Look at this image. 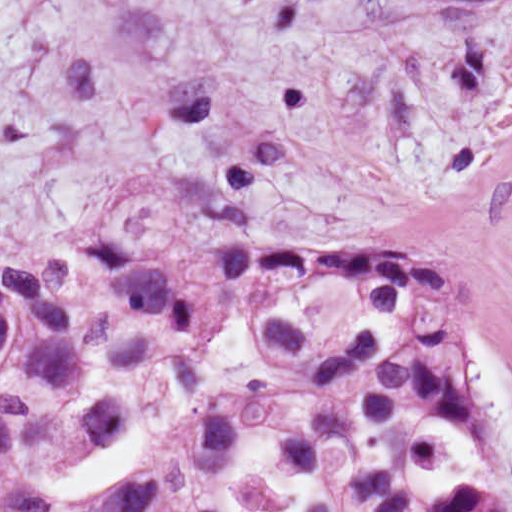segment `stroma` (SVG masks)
Instances as JSON below:
<instances>
[{
    "instance_id": "obj_1",
    "label": "stroma",
    "mask_w": 512,
    "mask_h": 512,
    "mask_svg": "<svg viewBox=\"0 0 512 512\" xmlns=\"http://www.w3.org/2000/svg\"><path fill=\"white\" fill-rule=\"evenodd\" d=\"M210 187L424 257L512 375V0H0V269L126 229L195 260Z\"/></svg>"
}]
</instances>
